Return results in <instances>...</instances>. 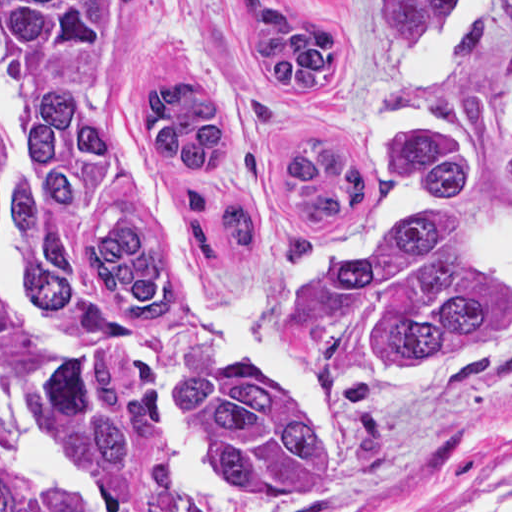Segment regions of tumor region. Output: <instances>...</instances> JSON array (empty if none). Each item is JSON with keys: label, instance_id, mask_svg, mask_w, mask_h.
<instances>
[{"label": "tumor region", "instance_id": "1", "mask_svg": "<svg viewBox=\"0 0 512 512\" xmlns=\"http://www.w3.org/2000/svg\"><path fill=\"white\" fill-rule=\"evenodd\" d=\"M386 46L390 192L261 355L183 259L250 251L251 202L193 194L249 63L284 102L364 70L317 0H214L124 85L108 0H0V512H285L339 484L370 393L462 389L512 358V82L481 61L512 0H367Z\"/></svg>", "mask_w": 512, "mask_h": 512}]
</instances>
